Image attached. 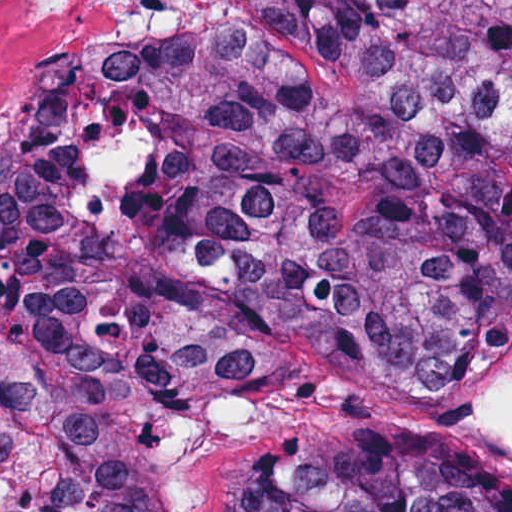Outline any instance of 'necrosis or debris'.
Wrapping results in <instances>:
<instances>
[{"mask_svg": "<svg viewBox=\"0 0 512 512\" xmlns=\"http://www.w3.org/2000/svg\"><path fill=\"white\" fill-rule=\"evenodd\" d=\"M178 0H0V147Z\"/></svg>", "mask_w": 512, "mask_h": 512, "instance_id": "1", "label": "necrosis or debris"}]
</instances>
